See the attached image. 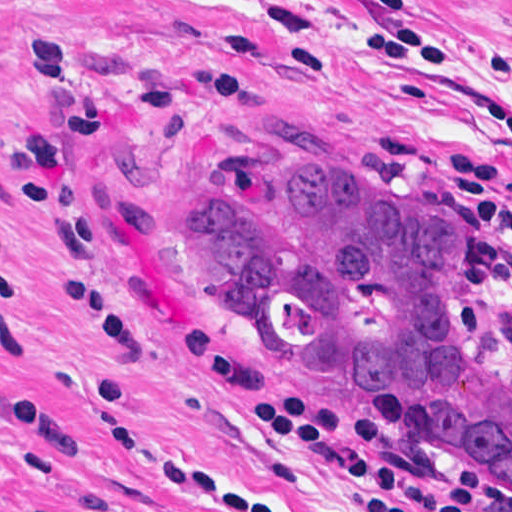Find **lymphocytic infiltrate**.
<instances>
[{
  "mask_svg": "<svg viewBox=\"0 0 512 512\" xmlns=\"http://www.w3.org/2000/svg\"><path fill=\"white\" fill-rule=\"evenodd\" d=\"M492 150H512V146ZM173 332L198 369L212 379L240 389L247 418L275 439L320 459L359 484L422 512H476L483 501L486 474L482 471H465L454 488H438L412 480L378 458L376 450L384 434L375 420L359 421L357 431L362 440L351 441L345 432L343 412L334 404L296 392L270 393L257 374L237 364L207 333L190 326ZM161 480L180 486L214 512H282L235 492L212 478L209 469L186 460ZM354 506L359 512H401L357 491ZM484 512H512V504Z\"/></svg>",
  "mask_w": 512,
  "mask_h": 512,
  "instance_id": "f902f5d3",
  "label": "lymphocytic infiltrate"
}]
</instances>
